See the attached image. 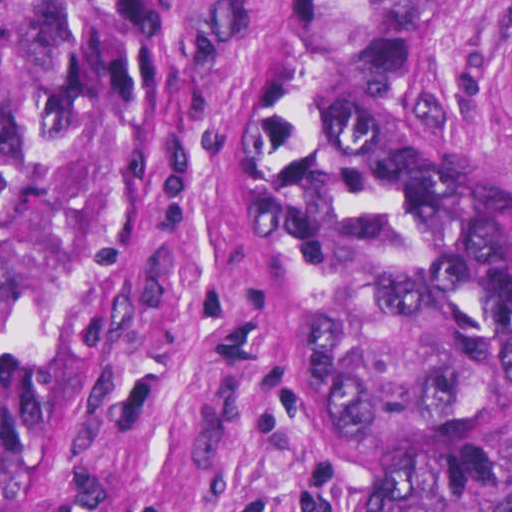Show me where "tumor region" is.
Masks as SVG:
<instances>
[{"label":"tumor region","mask_w":512,"mask_h":512,"mask_svg":"<svg viewBox=\"0 0 512 512\" xmlns=\"http://www.w3.org/2000/svg\"><path fill=\"white\" fill-rule=\"evenodd\" d=\"M467 1H275L236 122L273 364L364 452L360 512H512V186L427 90ZM148 96L130 1H0V512H36ZM479 104L512 142V33Z\"/></svg>","instance_id":"e687c5a6"}]
</instances>
